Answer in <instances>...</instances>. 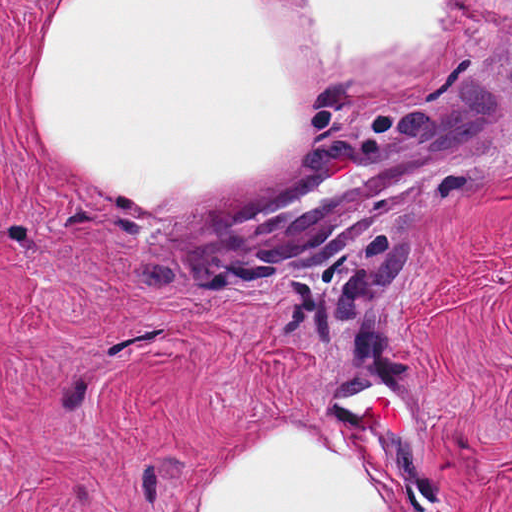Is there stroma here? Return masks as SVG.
<instances>
[{
    "instance_id": "stroma-1",
    "label": "stroma",
    "mask_w": 512,
    "mask_h": 512,
    "mask_svg": "<svg viewBox=\"0 0 512 512\" xmlns=\"http://www.w3.org/2000/svg\"><path fill=\"white\" fill-rule=\"evenodd\" d=\"M72 1H459L437 72L332 108L286 179L461 101L490 139L328 239L192 263L206 208L107 200L46 148L34 80ZM280 433L399 512H512V0H0V512H186Z\"/></svg>"
}]
</instances>
